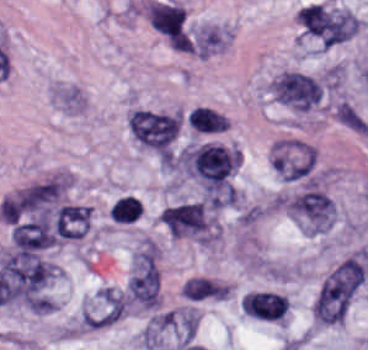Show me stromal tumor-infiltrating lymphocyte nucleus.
<instances>
[{"label":"stromal tumor-infiltrating lymphocyte nucleus","mask_w":368,"mask_h":350,"mask_svg":"<svg viewBox=\"0 0 368 350\" xmlns=\"http://www.w3.org/2000/svg\"><path fill=\"white\" fill-rule=\"evenodd\" d=\"M289 305L288 298L278 291L252 290L245 293L242 309L264 319L283 320Z\"/></svg>","instance_id":"1"}]
</instances>
